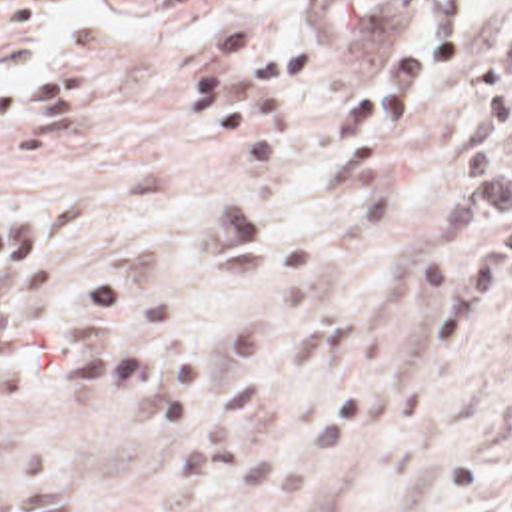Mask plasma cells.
Listing matches in <instances>:
<instances>
[{"label":"plasma cells","instance_id":"9512152a","mask_svg":"<svg viewBox=\"0 0 512 512\" xmlns=\"http://www.w3.org/2000/svg\"><path fill=\"white\" fill-rule=\"evenodd\" d=\"M473 85L481 107L459 143L432 231L454 237L473 211L481 235L430 251L438 293L430 347L479 335L511 277L512 25L477 51ZM272 255L274 229L258 211L216 207L182 229L174 309L156 305L112 265H88L64 293V229L54 213L0 211V404L26 394L36 370H50L62 392L178 428L172 484L180 498H260L316 478L244 436L280 392L274 327L244 323L208 345L192 339L218 299L266 275Z\"/></svg>","mask_w":512,"mask_h":512}]
</instances>
